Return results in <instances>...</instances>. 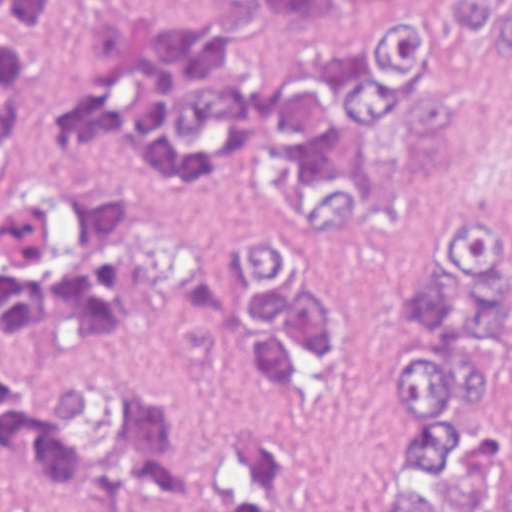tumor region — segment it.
<instances>
[{"instance_id": "1", "label": "tumor region", "mask_w": 512, "mask_h": 512, "mask_svg": "<svg viewBox=\"0 0 512 512\" xmlns=\"http://www.w3.org/2000/svg\"><path fill=\"white\" fill-rule=\"evenodd\" d=\"M201 25L157 23L151 8L91 24L100 76L61 103L54 133L26 121V67L0 74V157L29 144L38 178L0 215V331L52 325L107 336L134 303L174 297L183 281L182 218L196 197L189 170L158 163L151 109L171 155L202 158L224 132L252 121L313 196L309 223L254 232L247 358L281 393L286 347L331 345V307L299 296L282 234L337 218L350 186L321 181L358 123L397 94L418 167L449 164L452 90L426 72L448 29L475 26L509 60L512 6L457 0L446 22L382 21L362 44L307 47L268 81L189 74L195 49L245 36L255 18L331 0H246ZM423 275L403 287L391 327L403 364L391 404L403 426L379 459L375 512H512V209L436 214L423 233ZM0 451L53 493L141 497L165 486L179 452L177 401L143 368L105 358L21 377L0 368ZM284 465L254 441L214 459L188 512H279ZM0 512H5L0 509Z\"/></svg>"}]
</instances>
